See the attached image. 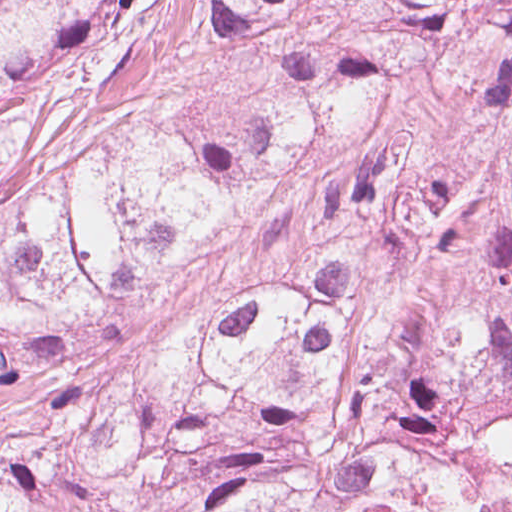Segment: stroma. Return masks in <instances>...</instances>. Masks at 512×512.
Segmentation results:
<instances>
[{
    "label": "stroma",
    "instance_id": "obj_1",
    "mask_svg": "<svg viewBox=\"0 0 512 512\" xmlns=\"http://www.w3.org/2000/svg\"><path fill=\"white\" fill-rule=\"evenodd\" d=\"M457 165V114L439 87L415 72L386 96L365 132L275 196L253 204L166 289L81 330L76 361L97 374H118L138 363L150 370L164 340L189 330L232 294L312 275L355 197L380 192L394 179L443 184ZM21 396L22 387H0V436Z\"/></svg>",
    "mask_w": 512,
    "mask_h": 512
}]
</instances>
